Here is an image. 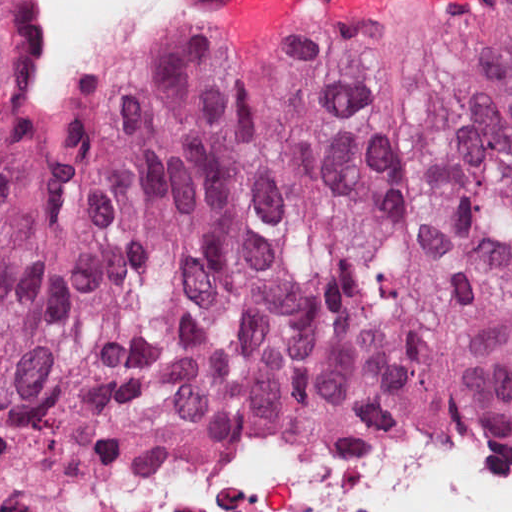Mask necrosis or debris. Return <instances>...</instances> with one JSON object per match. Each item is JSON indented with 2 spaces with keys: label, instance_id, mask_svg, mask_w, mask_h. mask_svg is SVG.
Wrapping results in <instances>:
<instances>
[{
  "label": "necrosis or debris",
  "instance_id": "obj_1",
  "mask_svg": "<svg viewBox=\"0 0 512 512\" xmlns=\"http://www.w3.org/2000/svg\"><path fill=\"white\" fill-rule=\"evenodd\" d=\"M97 512H512V442L330 448L229 427L90 485Z\"/></svg>",
  "mask_w": 512,
  "mask_h": 512
}]
</instances>
